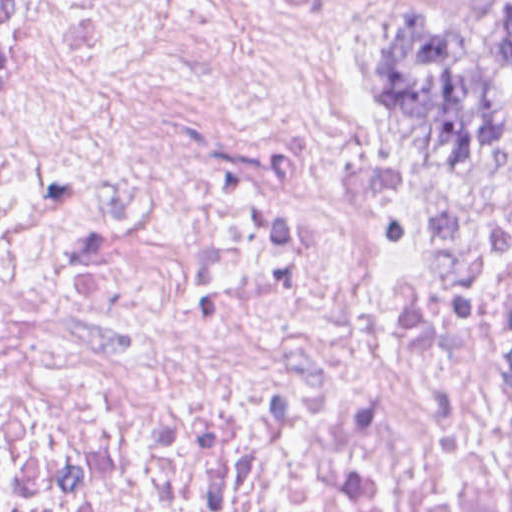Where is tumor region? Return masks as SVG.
Returning <instances> with one entry per match:
<instances>
[{
  "mask_svg": "<svg viewBox=\"0 0 512 512\" xmlns=\"http://www.w3.org/2000/svg\"><path fill=\"white\" fill-rule=\"evenodd\" d=\"M378 78L449 170L464 178L512 171V0L379 18Z\"/></svg>",
  "mask_w": 512,
  "mask_h": 512,
  "instance_id": "obj_1",
  "label": "tumor region"
}]
</instances>
